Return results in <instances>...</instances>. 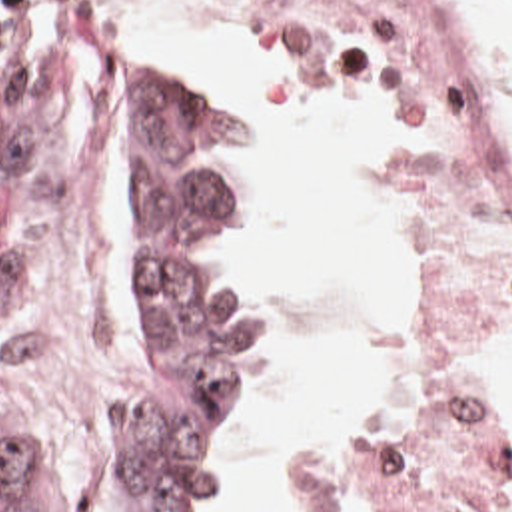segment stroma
I'll return each mask as SVG.
<instances>
[{
  "instance_id": "stroma-1",
  "label": "stroma",
  "mask_w": 512,
  "mask_h": 512,
  "mask_svg": "<svg viewBox=\"0 0 512 512\" xmlns=\"http://www.w3.org/2000/svg\"><path fill=\"white\" fill-rule=\"evenodd\" d=\"M183 2L243 20L257 34L271 72L301 94L371 102L403 122V152L393 162L395 238L399 180L413 144L411 88L369 78L345 64L309 38L275 2ZM428 2L466 86L472 124L494 182L512 208V160L480 60L464 40L460 20L448 2ZM0 4L47 6L57 12H105L137 32L199 84L231 102L247 118L259 148V210L235 254L217 268L197 276V280L207 298L245 314L253 324L259 342L261 379L265 328L259 312L239 298L231 278L241 258L263 246L273 232V148L269 134L241 100L233 80L211 66L173 54L147 26L123 18L105 2L0 0ZM33 200L37 210L33 340L21 368L0 374V413L27 437L39 471L61 512L139 509L113 483L107 463L111 395L117 374L131 352L139 320V208L133 190L109 148L65 120L45 156ZM500 340L512 342V332ZM472 383L484 413L512 443L510 415L486 395L482 358ZM393 389L395 372L385 399ZM385 399L355 411H377ZM249 411L251 401L245 427ZM227 471L229 463L223 471L221 487ZM295 473L279 512H297L293 495Z\"/></svg>"
}]
</instances>
